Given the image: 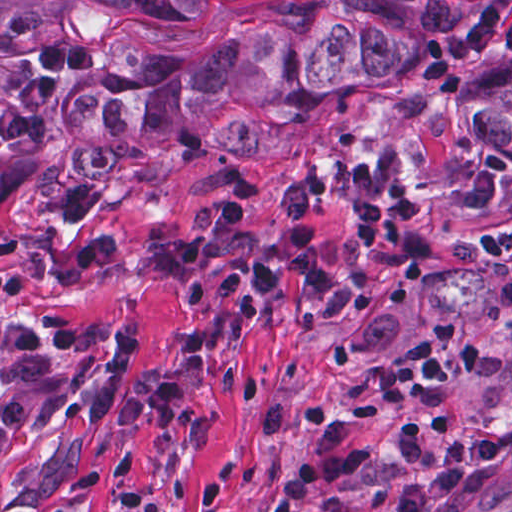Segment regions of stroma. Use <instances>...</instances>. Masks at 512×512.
Returning a JSON list of instances; mask_svg holds the SVG:
<instances>
[{
	"mask_svg": "<svg viewBox=\"0 0 512 512\" xmlns=\"http://www.w3.org/2000/svg\"><path fill=\"white\" fill-rule=\"evenodd\" d=\"M268 1L198 0L192 17L124 18L90 0H0V47L32 63L37 46L90 43L102 48L96 75L124 46L197 56ZM473 1L482 9L489 0ZM509 72L501 35L459 73L457 96L420 76L327 97L309 125L262 119L258 127L283 142L281 155L231 154L168 132L114 178L91 179V226L117 251L78 284L55 278L77 240L57 208L90 179L79 149L99 142L71 104L61 132L29 150L1 151L0 268L25 276L31 295L1 302L0 319L49 336L71 398L22 433L0 425V512H275L276 487L313 443L305 404L346 414L399 362L422 353L443 314L480 339L483 364L431 400L459 411L451 432L433 436L440 456L427 466L399 460L400 412L378 426L355 424L350 435L368 462L310 494L301 512H393L411 481L439 469L453 440L502 428L512 408V305L483 237L512 231V152L473 142L466 100L484 79ZM237 172L251 178L240 237L264 250L278 224L279 189L324 179L315 235L336 270L361 287L352 313L298 317L280 276L273 290L248 291L263 311L228 313L211 296L223 269L211 258L197 302L137 276L136 259L183 238L189 204L215 196ZM400 183L433 192L437 247L417 272H372L359 261L354 211ZM15 378L0 367V406ZM421 512H512V444L479 490Z\"/></svg>",
	"mask_w": 512,
	"mask_h": 512,
	"instance_id": "35a3bbf8",
	"label": "stroma"
}]
</instances>
